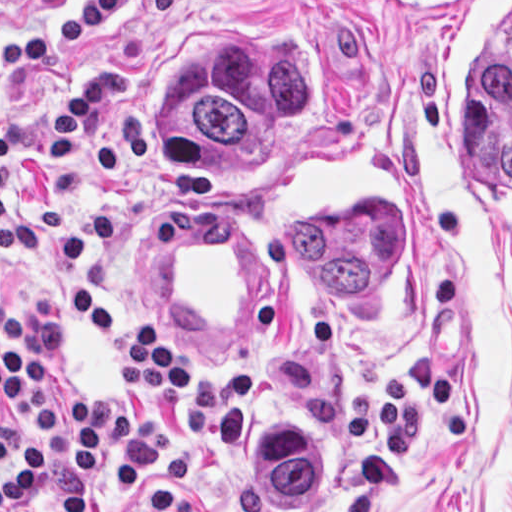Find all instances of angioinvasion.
<instances>
[{"instance_id":"e142278d","label":"angioinvasion","mask_w":512,"mask_h":512,"mask_svg":"<svg viewBox=\"0 0 512 512\" xmlns=\"http://www.w3.org/2000/svg\"><path fill=\"white\" fill-rule=\"evenodd\" d=\"M308 148L255 186V209L278 257L354 375L415 363L434 336V275L414 188L357 138ZM419 176L447 211L512 230V1H449L418 112ZM401 210L403 255L362 296L305 267L286 231L290 210Z\"/></svg>"}]
</instances>
